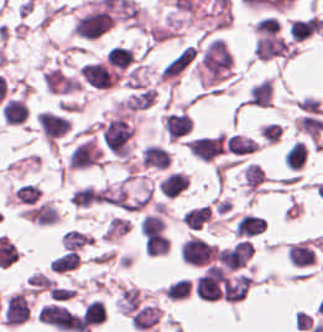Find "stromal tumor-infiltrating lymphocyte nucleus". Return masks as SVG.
Here are the masks:
<instances>
[{
  "label": "stromal tumor-infiltrating lymphocyte nucleus",
  "instance_id": "1",
  "mask_svg": "<svg viewBox=\"0 0 323 332\" xmlns=\"http://www.w3.org/2000/svg\"><path fill=\"white\" fill-rule=\"evenodd\" d=\"M38 320L56 329L82 332V323L78 314L53 303L40 308Z\"/></svg>",
  "mask_w": 323,
  "mask_h": 332
},
{
  "label": "stromal tumor-infiltrating lymphocyte nucleus",
  "instance_id": "2",
  "mask_svg": "<svg viewBox=\"0 0 323 332\" xmlns=\"http://www.w3.org/2000/svg\"><path fill=\"white\" fill-rule=\"evenodd\" d=\"M186 144L196 158L210 162L223 152L225 133L190 138Z\"/></svg>",
  "mask_w": 323,
  "mask_h": 332
},
{
  "label": "stromal tumor-infiltrating lymphocyte nucleus",
  "instance_id": "3",
  "mask_svg": "<svg viewBox=\"0 0 323 332\" xmlns=\"http://www.w3.org/2000/svg\"><path fill=\"white\" fill-rule=\"evenodd\" d=\"M30 316V306L24 292H16L4 305L3 323L8 327H15Z\"/></svg>",
  "mask_w": 323,
  "mask_h": 332
},
{
  "label": "stromal tumor-infiltrating lymphocyte nucleus",
  "instance_id": "4",
  "mask_svg": "<svg viewBox=\"0 0 323 332\" xmlns=\"http://www.w3.org/2000/svg\"><path fill=\"white\" fill-rule=\"evenodd\" d=\"M163 127L169 139L177 140L192 129V119L184 112H169L164 116Z\"/></svg>",
  "mask_w": 323,
  "mask_h": 332
},
{
  "label": "stromal tumor-infiltrating lymphocyte nucleus",
  "instance_id": "5",
  "mask_svg": "<svg viewBox=\"0 0 323 332\" xmlns=\"http://www.w3.org/2000/svg\"><path fill=\"white\" fill-rule=\"evenodd\" d=\"M171 161L170 153L156 143H149L142 150L143 167L166 169Z\"/></svg>",
  "mask_w": 323,
  "mask_h": 332
},
{
  "label": "stromal tumor-infiltrating lymphocyte nucleus",
  "instance_id": "6",
  "mask_svg": "<svg viewBox=\"0 0 323 332\" xmlns=\"http://www.w3.org/2000/svg\"><path fill=\"white\" fill-rule=\"evenodd\" d=\"M287 256L295 266L313 265L315 261L314 249L308 240H300L288 245Z\"/></svg>",
  "mask_w": 323,
  "mask_h": 332
},
{
  "label": "stromal tumor-infiltrating lymphocyte nucleus",
  "instance_id": "7",
  "mask_svg": "<svg viewBox=\"0 0 323 332\" xmlns=\"http://www.w3.org/2000/svg\"><path fill=\"white\" fill-rule=\"evenodd\" d=\"M189 174L170 172L162 181L160 194L168 199H175L189 188Z\"/></svg>",
  "mask_w": 323,
  "mask_h": 332
},
{
  "label": "stromal tumor-infiltrating lymphocyte nucleus",
  "instance_id": "8",
  "mask_svg": "<svg viewBox=\"0 0 323 332\" xmlns=\"http://www.w3.org/2000/svg\"><path fill=\"white\" fill-rule=\"evenodd\" d=\"M266 226L262 217L247 213L237 220L233 232L240 237L253 236L260 234Z\"/></svg>",
  "mask_w": 323,
  "mask_h": 332
},
{
  "label": "stromal tumor-infiltrating lymphocyte nucleus",
  "instance_id": "9",
  "mask_svg": "<svg viewBox=\"0 0 323 332\" xmlns=\"http://www.w3.org/2000/svg\"><path fill=\"white\" fill-rule=\"evenodd\" d=\"M160 310L156 305H143L133 312L131 325L139 329H149L159 320Z\"/></svg>",
  "mask_w": 323,
  "mask_h": 332
},
{
  "label": "stromal tumor-infiltrating lymphocyte nucleus",
  "instance_id": "10",
  "mask_svg": "<svg viewBox=\"0 0 323 332\" xmlns=\"http://www.w3.org/2000/svg\"><path fill=\"white\" fill-rule=\"evenodd\" d=\"M0 109L4 121L15 125L21 123L27 116L25 102L16 97H9Z\"/></svg>",
  "mask_w": 323,
  "mask_h": 332
},
{
  "label": "stromal tumor-infiltrating lymphocyte nucleus",
  "instance_id": "11",
  "mask_svg": "<svg viewBox=\"0 0 323 332\" xmlns=\"http://www.w3.org/2000/svg\"><path fill=\"white\" fill-rule=\"evenodd\" d=\"M258 144L259 142L236 133L226 138V149L231 154L243 156L251 154Z\"/></svg>",
  "mask_w": 323,
  "mask_h": 332
},
{
  "label": "stromal tumor-infiltrating lymphocyte nucleus",
  "instance_id": "12",
  "mask_svg": "<svg viewBox=\"0 0 323 332\" xmlns=\"http://www.w3.org/2000/svg\"><path fill=\"white\" fill-rule=\"evenodd\" d=\"M308 147L303 141H295L284 153L283 162L287 168L300 170L307 156Z\"/></svg>",
  "mask_w": 323,
  "mask_h": 332
},
{
  "label": "stromal tumor-infiltrating lymphocyte nucleus",
  "instance_id": "13",
  "mask_svg": "<svg viewBox=\"0 0 323 332\" xmlns=\"http://www.w3.org/2000/svg\"><path fill=\"white\" fill-rule=\"evenodd\" d=\"M211 219V213L207 204L189 209L182 217L183 223L188 229L199 230Z\"/></svg>",
  "mask_w": 323,
  "mask_h": 332
},
{
  "label": "stromal tumor-infiltrating lymphocyte nucleus",
  "instance_id": "14",
  "mask_svg": "<svg viewBox=\"0 0 323 332\" xmlns=\"http://www.w3.org/2000/svg\"><path fill=\"white\" fill-rule=\"evenodd\" d=\"M100 193L92 186L78 188L70 197V203L76 208H87L96 203Z\"/></svg>",
  "mask_w": 323,
  "mask_h": 332
},
{
  "label": "stromal tumor-infiltrating lymphocyte nucleus",
  "instance_id": "15",
  "mask_svg": "<svg viewBox=\"0 0 323 332\" xmlns=\"http://www.w3.org/2000/svg\"><path fill=\"white\" fill-rule=\"evenodd\" d=\"M104 316L105 310L98 300H91L83 306L82 320L91 327L104 322Z\"/></svg>",
  "mask_w": 323,
  "mask_h": 332
},
{
  "label": "stromal tumor-infiltrating lymphocyte nucleus",
  "instance_id": "16",
  "mask_svg": "<svg viewBox=\"0 0 323 332\" xmlns=\"http://www.w3.org/2000/svg\"><path fill=\"white\" fill-rule=\"evenodd\" d=\"M79 258L76 250H69L52 259L50 270L52 272H65L77 267Z\"/></svg>",
  "mask_w": 323,
  "mask_h": 332
},
{
  "label": "stromal tumor-infiltrating lymphocyte nucleus",
  "instance_id": "17",
  "mask_svg": "<svg viewBox=\"0 0 323 332\" xmlns=\"http://www.w3.org/2000/svg\"><path fill=\"white\" fill-rule=\"evenodd\" d=\"M40 188L32 183H25L18 187L14 196L18 203L34 204L40 197Z\"/></svg>",
  "mask_w": 323,
  "mask_h": 332
}]
</instances>
